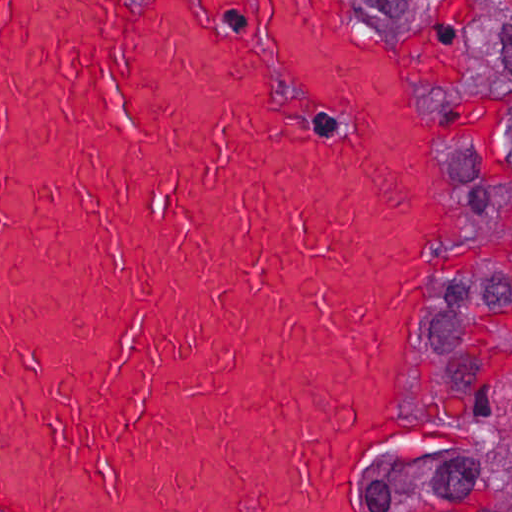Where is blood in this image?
Here are the masks:
<instances>
[{"label":"blood","instance_id":"obj_1","mask_svg":"<svg viewBox=\"0 0 512 512\" xmlns=\"http://www.w3.org/2000/svg\"><path fill=\"white\" fill-rule=\"evenodd\" d=\"M441 189L351 0H0V512H382Z\"/></svg>","mask_w":512,"mask_h":512}]
</instances>
